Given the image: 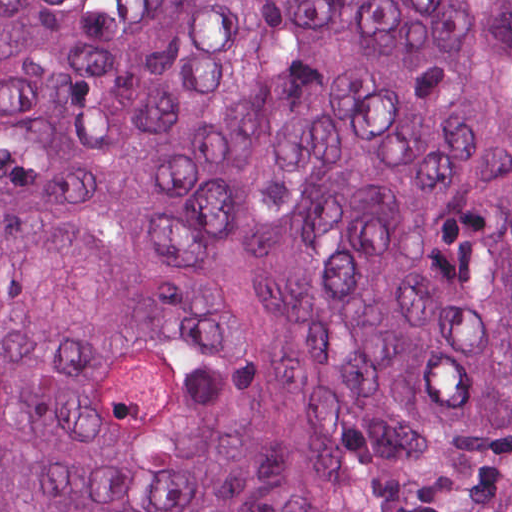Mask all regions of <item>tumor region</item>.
<instances>
[{
  "instance_id": "tumor-region-1",
  "label": "tumor region",
  "mask_w": 512,
  "mask_h": 512,
  "mask_svg": "<svg viewBox=\"0 0 512 512\" xmlns=\"http://www.w3.org/2000/svg\"><path fill=\"white\" fill-rule=\"evenodd\" d=\"M0 512H512V0H0Z\"/></svg>"
}]
</instances>
